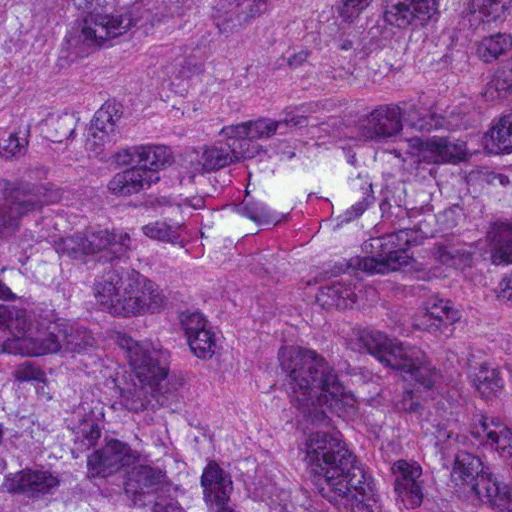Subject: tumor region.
Here are the masks:
<instances>
[{
  "label": "tumor region",
  "mask_w": 512,
  "mask_h": 512,
  "mask_svg": "<svg viewBox=\"0 0 512 512\" xmlns=\"http://www.w3.org/2000/svg\"><path fill=\"white\" fill-rule=\"evenodd\" d=\"M0 512H512V0H0Z\"/></svg>",
  "instance_id": "tumor-region-1"
}]
</instances>
